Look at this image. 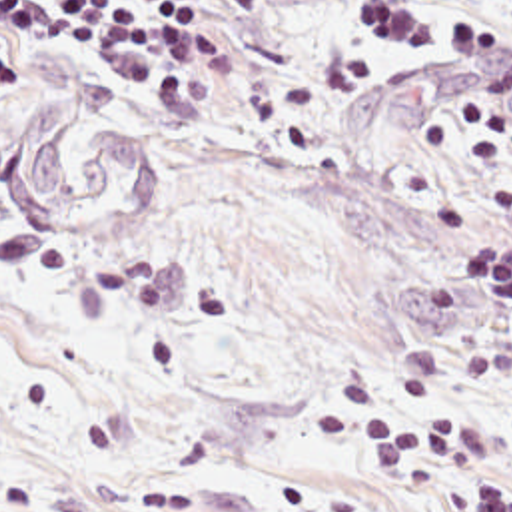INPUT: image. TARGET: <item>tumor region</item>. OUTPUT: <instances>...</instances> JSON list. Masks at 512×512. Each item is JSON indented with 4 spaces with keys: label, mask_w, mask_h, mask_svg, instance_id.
Instances as JSON below:
<instances>
[{
    "label": "tumor region",
    "mask_w": 512,
    "mask_h": 512,
    "mask_svg": "<svg viewBox=\"0 0 512 512\" xmlns=\"http://www.w3.org/2000/svg\"><path fill=\"white\" fill-rule=\"evenodd\" d=\"M0 133V197L24 227H86L164 183L160 151L148 137L120 127L94 129L68 157L60 143L72 111L68 91L30 97Z\"/></svg>",
    "instance_id": "obj_1"
}]
</instances>
